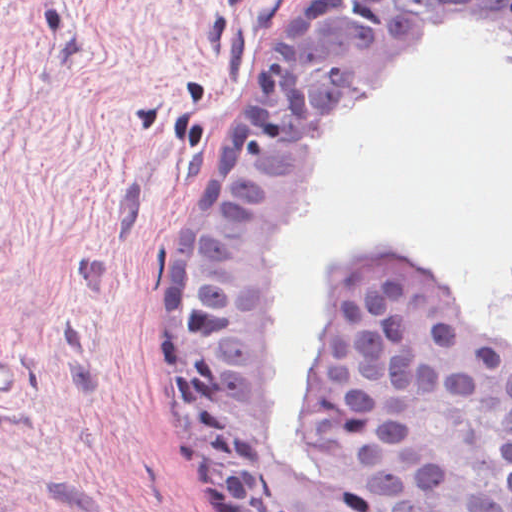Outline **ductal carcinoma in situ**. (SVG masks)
<instances>
[{
    "instance_id": "obj_1",
    "label": "ductal carcinoma in situ",
    "mask_w": 512,
    "mask_h": 512,
    "mask_svg": "<svg viewBox=\"0 0 512 512\" xmlns=\"http://www.w3.org/2000/svg\"><path fill=\"white\" fill-rule=\"evenodd\" d=\"M512 28V0H296L240 112L175 193L162 245V367L184 438L240 512H512V344L474 341L432 274L361 251L313 343L311 483L264 406L271 249L362 105L437 21Z\"/></svg>"
}]
</instances>
